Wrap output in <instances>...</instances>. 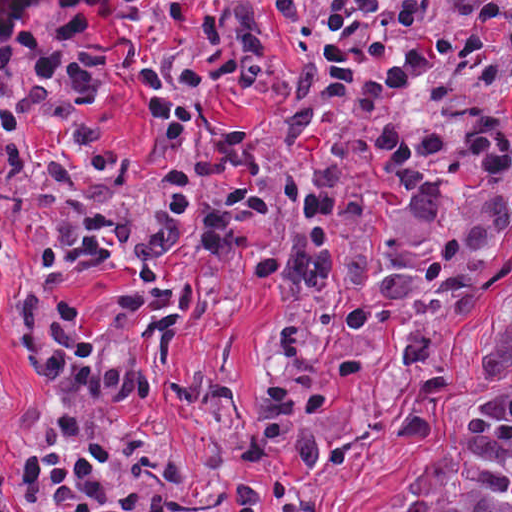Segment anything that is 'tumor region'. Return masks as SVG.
I'll list each match as a JSON object with an SVG mask.
<instances>
[{
	"label": "tumor region",
	"instance_id": "1",
	"mask_svg": "<svg viewBox=\"0 0 512 512\" xmlns=\"http://www.w3.org/2000/svg\"><path fill=\"white\" fill-rule=\"evenodd\" d=\"M480 365V394L418 463L393 512H512V303Z\"/></svg>",
	"mask_w": 512,
	"mask_h": 512
}]
</instances>
